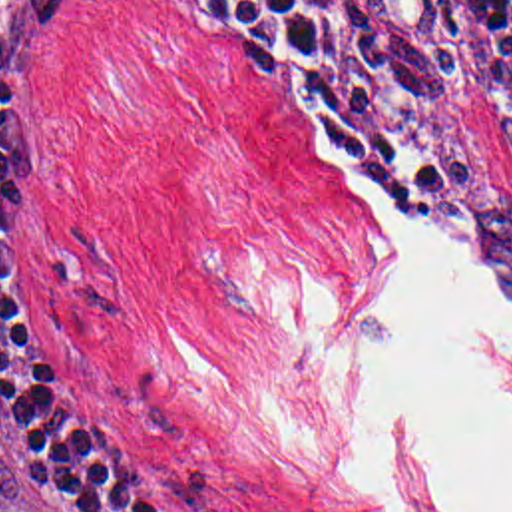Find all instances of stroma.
<instances>
[{
	"label": "stroma",
	"mask_w": 512,
	"mask_h": 512,
	"mask_svg": "<svg viewBox=\"0 0 512 512\" xmlns=\"http://www.w3.org/2000/svg\"><path fill=\"white\" fill-rule=\"evenodd\" d=\"M11 0H0V3ZM413 213H374L228 51L147 0H61L21 69L3 280L55 394L150 442L198 512H395L290 328L350 324L403 232L512 298L511 41L445 0H338ZM465 370L512 412V344ZM0 512H61L0 448Z\"/></svg>",
	"instance_id": "stroma-1"
}]
</instances>
